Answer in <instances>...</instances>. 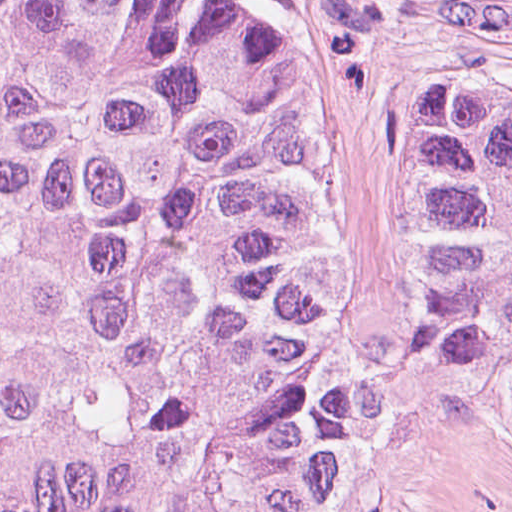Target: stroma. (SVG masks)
Returning <instances> with one entry per match:
<instances>
[{"instance_id": "1", "label": "stroma", "mask_w": 512, "mask_h": 512, "mask_svg": "<svg viewBox=\"0 0 512 512\" xmlns=\"http://www.w3.org/2000/svg\"><path fill=\"white\" fill-rule=\"evenodd\" d=\"M321 58V260L379 458L341 512H512V433L464 398L411 287L393 97L410 75L512 96V0H221Z\"/></svg>"}]
</instances>
